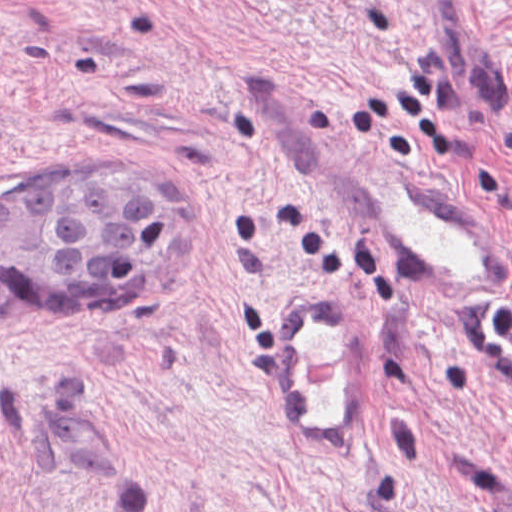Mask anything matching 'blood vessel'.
Masks as SVG:
<instances>
[{"label": "blood vessel", "mask_w": 512, "mask_h": 512, "mask_svg": "<svg viewBox=\"0 0 512 512\" xmlns=\"http://www.w3.org/2000/svg\"><path fill=\"white\" fill-rule=\"evenodd\" d=\"M328 182L343 217L445 317H507L512 267L431 179L402 162L349 154ZM271 329L297 420L315 451L371 437V319L331 290L273 297Z\"/></svg>", "instance_id": "obj_1"}]
</instances>
